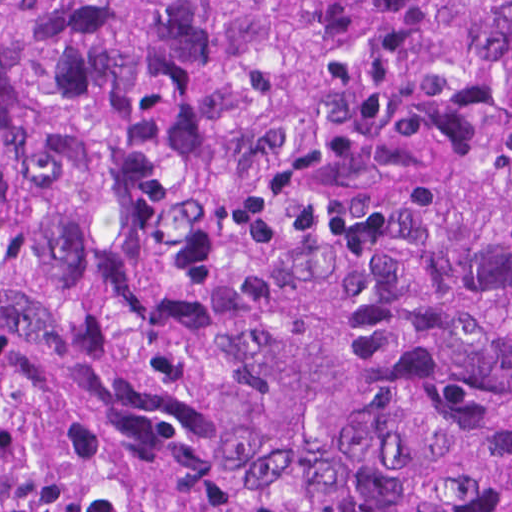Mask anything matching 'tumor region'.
I'll return each mask as SVG.
<instances>
[{"instance_id":"e687c5a6","label":"tumor region","mask_w":512,"mask_h":512,"mask_svg":"<svg viewBox=\"0 0 512 512\" xmlns=\"http://www.w3.org/2000/svg\"><path fill=\"white\" fill-rule=\"evenodd\" d=\"M0 512H512V0H0Z\"/></svg>"}]
</instances>
